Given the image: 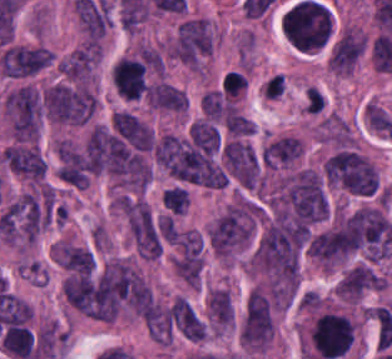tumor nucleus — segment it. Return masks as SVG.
I'll return each instance as SVG.
<instances>
[{"label":"tumor nucleus","instance_id":"2f306a5c","mask_svg":"<svg viewBox=\"0 0 392 359\" xmlns=\"http://www.w3.org/2000/svg\"><path fill=\"white\" fill-rule=\"evenodd\" d=\"M253 216L249 205H230L209 226L207 238L213 252L229 258L251 241Z\"/></svg>","mask_w":392,"mask_h":359},{"label":"tumor nucleus","instance_id":"8643909e","mask_svg":"<svg viewBox=\"0 0 392 359\" xmlns=\"http://www.w3.org/2000/svg\"><path fill=\"white\" fill-rule=\"evenodd\" d=\"M325 177L331 184L361 194L375 192L378 183L371 161L346 147L334 153L325 163Z\"/></svg>","mask_w":392,"mask_h":359},{"label":"tumor nucleus","instance_id":"5ab6c2c4","mask_svg":"<svg viewBox=\"0 0 392 359\" xmlns=\"http://www.w3.org/2000/svg\"><path fill=\"white\" fill-rule=\"evenodd\" d=\"M273 332L267 299L255 286L245 305L241 328V342L250 349L264 350Z\"/></svg>","mask_w":392,"mask_h":359},{"label":"tumor nucleus","instance_id":"2cbd58db","mask_svg":"<svg viewBox=\"0 0 392 359\" xmlns=\"http://www.w3.org/2000/svg\"><path fill=\"white\" fill-rule=\"evenodd\" d=\"M42 46L5 44L0 55L3 77L26 78L44 69L52 60Z\"/></svg>","mask_w":392,"mask_h":359},{"label":"tumor nucleus","instance_id":"3d1891a8","mask_svg":"<svg viewBox=\"0 0 392 359\" xmlns=\"http://www.w3.org/2000/svg\"><path fill=\"white\" fill-rule=\"evenodd\" d=\"M134 246L139 256L156 257L161 253V243L150 211L143 200L127 202L124 210Z\"/></svg>","mask_w":392,"mask_h":359},{"label":"tumor nucleus","instance_id":"2083b535","mask_svg":"<svg viewBox=\"0 0 392 359\" xmlns=\"http://www.w3.org/2000/svg\"><path fill=\"white\" fill-rule=\"evenodd\" d=\"M227 168L238 183L253 187L258 174V161L251 145L243 141H230L222 148Z\"/></svg>","mask_w":392,"mask_h":359},{"label":"tumor nucleus","instance_id":"8087334f","mask_svg":"<svg viewBox=\"0 0 392 359\" xmlns=\"http://www.w3.org/2000/svg\"><path fill=\"white\" fill-rule=\"evenodd\" d=\"M112 84L119 96L127 99L140 97L148 87L142 62L121 57L112 66Z\"/></svg>","mask_w":392,"mask_h":359},{"label":"tumor nucleus","instance_id":"c2bd9aea","mask_svg":"<svg viewBox=\"0 0 392 359\" xmlns=\"http://www.w3.org/2000/svg\"><path fill=\"white\" fill-rule=\"evenodd\" d=\"M362 53L361 32L355 28L333 38L327 58L337 74H345L356 64Z\"/></svg>","mask_w":392,"mask_h":359},{"label":"tumor nucleus","instance_id":"feef74b5","mask_svg":"<svg viewBox=\"0 0 392 359\" xmlns=\"http://www.w3.org/2000/svg\"><path fill=\"white\" fill-rule=\"evenodd\" d=\"M148 103L149 106L184 112L188 107V98L173 84L158 82L148 86Z\"/></svg>","mask_w":392,"mask_h":359},{"label":"tumor nucleus","instance_id":"3e47fb67","mask_svg":"<svg viewBox=\"0 0 392 359\" xmlns=\"http://www.w3.org/2000/svg\"><path fill=\"white\" fill-rule=\"evenodd\" d=\"M207 300L212 325H232L233 306L226 290L221 287H213Z\"/></svg>","mask_w":392,"mask_h":359},{"label":"tumor nucleus","instance_id":"f7901128","mask_svg":"<svg viewBox=\"0 0 392 359\" xmlns=\"http://www.w3.org/2000/svg\"><path fill=\"white\" fill-rule=\"evenodd\" d=\"M302 152L277 137L271 140L270 168L293 166Z\"/></svg>","mask_w":392,"mask_h":359},{"label":"tumor nucleus","instance_id":"268c6acd","mask_svg":"<svg viewBox=\"0 0 392 359\" xmlns=\"http://www.w3.org/2000/svg\"><path fill=\"white\" fill-rule=\"evenodd\" d=\"M223 123L233 136H241L256 131L251 120L237 107H230Z\"/></svg>","mask_w":392,"mask_h":359},{"label":"tumor nucleus","instance_id":"1edb0cf7","mask_svg":"<svg viewBox=\"0 0 392 359\" xmlns=\"http://www.w3.org/2000/svg\"><path fill=\"white\" fill-rule=\"evenodd\" d=\"M188 200V191L183 187L172 186L162 191V203L176 215L184 214Z\"/></svg>","mask_w":392,"mask_h":359},{"label":"tumor nucleus","instance_id":"962dda3e","mask_svg":"<svg viewBox=\"0 0 392 359\" xmlns=\"http://www.w3.org/2000/svg\"><path fill=\"white\" fill-rule=\"evenodd\" d=\"M247 84V77L242 71H228L223 82L222 94L236 97L242 94Z\"/></svg>","mask_w":392,"mask_h":359},{"label":"tumor nucleus","instance_id":"80c4ae96","mask_svg":"<svg viewBox=\"0 0 392 359\" xmlns=\"http://www.w3.org/2000/svg\"><path fill=\"white\" fill-rule=\"evenodd\" d=\"M325 104V97L315 87H307L304 98V109L306 113L320 114Z\"/></svg>","mask_w":392,"mask_h":359},{"label":"tumor nucleus","instance_id":"3d7bf9ca","mask_svg":"<svg viewBox=\"0 0 392 359\" xmlns=\"http://www.w3.org/2000/svg\"><path fill=\"white\" fill-rule=\"evenodd\" d=\"M156 228L163 240L177 242L178 230L172 216L158 215Z\"/></svg>","mask_w":392,"mask_h":359},{"label":"tumor nucleus","instance_id":"b15415a9","mask_svg":"<svg viewBox=\"0 0 392 359\" xmlns=\"http://www.w3.org/2000/svg\"><path fill=\"white\" fill-rule=\"evenodd\" d=\"M285 87L284 78L282 73H275L268 78L265 88L263 90V96L276 98L279 97Z\"/></svg>","mask_w":392,"mask_h":359}]
</instances>
